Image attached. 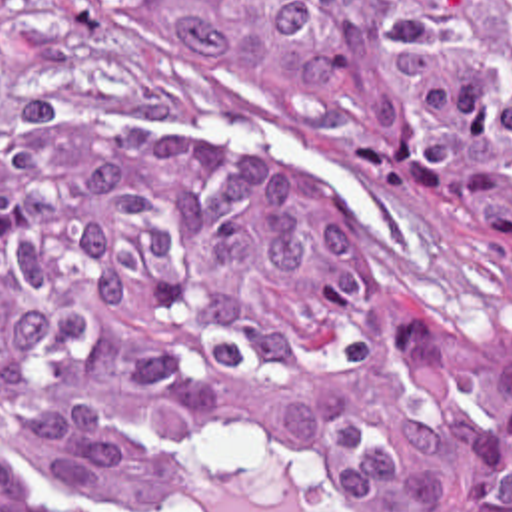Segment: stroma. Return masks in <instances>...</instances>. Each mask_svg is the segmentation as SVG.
I'll return each instance as SVG.
<instances>
[{"label":"stroma","mask_w":512,"mask_h":512,"mask_svg":"<svg viewBox=\"0 0 512 512\" xmlns=\"http://www.w3.org/2000/svg\"><path fill=\"white\" fill-rule=\"evenodd\" d=\"M147 110L227 136L263 160L335 194L375 236L405 292L512 356V236L441 168H355L295 140L271 100L149 92ZM0 452L35 484L85 512H121L21 420L0 418ZM431 512H471L427 480ZM185 512H351L285 450L207 446Z\"/></svg>","instance_id":"obj_1"}]
</instances>
